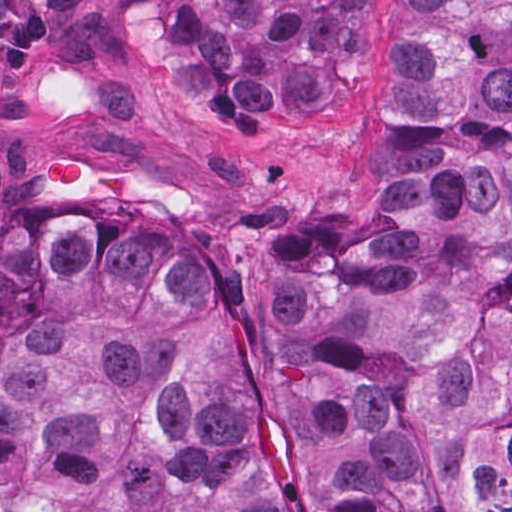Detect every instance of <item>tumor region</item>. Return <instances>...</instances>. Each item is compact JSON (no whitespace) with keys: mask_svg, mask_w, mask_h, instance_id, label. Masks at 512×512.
I'll use <instances>...</instances> for the list:
<instances>
[{"mask_svg":"<svg viewBox=\"0 0 512 512\" xmlns=\"http://www.w3.org/2000/svg\"><path fill=\"white\" fill-rule=\"evenodd\" d=\"M190 117L334 103L364 1H119ZM74 149L55 191L98 186ZM271 387L320 512H512V1H393L377 204L259 242ZM0 512H279L244 351L163 239L85 209L0 239Z\"/></svg>","mask_w":512,"mask_h":512,"instance_id":"tumor-region-1","label":"tumor region"}]
</instances>
